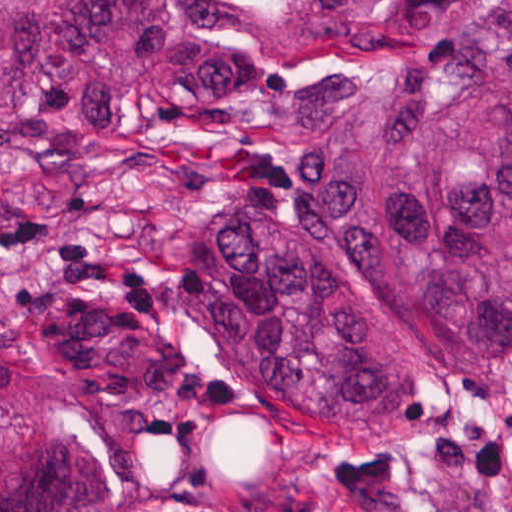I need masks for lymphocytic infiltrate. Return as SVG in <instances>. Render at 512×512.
<instances>
[{
	"mask_svg": "<svg viewBox=\"0 0 512 512\" xmlns=\"http://www.w3.org/2000/svg\"><path fill=\"white\" fill-rule=\"evenodd\" d=\"M32 242H40L46 248L65 278L112 290L116 295L114 326L128 338H147L149 313L158 309V298L146 286L142 269L107 256L87 240L62 233L44 218L23 217L1 224L0 248L24 247Z\"/></svg>",
	"mask_w": 512,
	"mask_h": 512,
	"instance_id": "lymphocytic-infiltrate-1",
	"label": "lymphocytic infiltrate"
}]
</instances>
